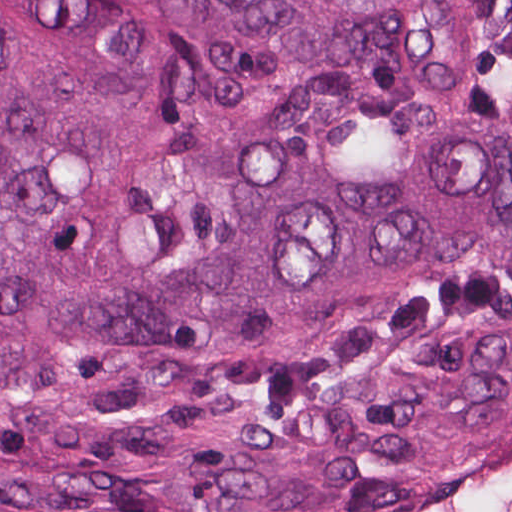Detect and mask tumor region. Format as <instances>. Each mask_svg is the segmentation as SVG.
Returning a JSON list of instances; mask_svg holds the SVG:
<instances>
[{
  "label": "tumor region",
  "mask_w": 512,
  "mask_h": 512,
  "mask_svg": "<svg viewBox=\"0 0 512 512\" xmlns=\"http://www.w3.org/2000/svg\"><path fill=\"white\" fill-rule=\"evenodd\" d=\"M512 423V0H0V512H353Z\"/></svg>",
  "instance_id": "tumor-region-1"
}]
</instances>
